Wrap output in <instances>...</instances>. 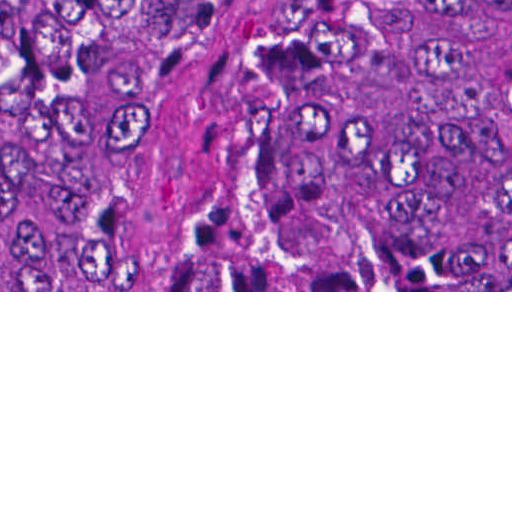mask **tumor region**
I'll list each match as a JSON object with an SVG mask.
<instances>
[{
  "mask_svg": "<svg viewBox=\"0 0 512 512\" xmlns=\"http://www.w3.org/2000/svg\"><path fill=\"white\" fill-rule=\"evenodd\" d=\"M221 82L303 264L512 290V0H1V290H118Z\"/></svg>",
  "mask_w": 512,
  "mask_h": 512,
  "instance_id": "e687c5a6",
  "label": "tumor region"
}]
</instances>
